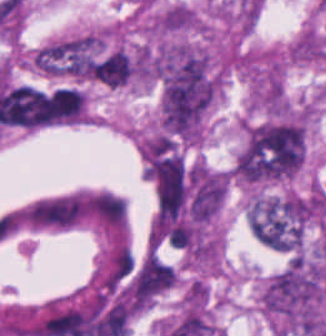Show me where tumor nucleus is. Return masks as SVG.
<instances>
[{"label": "tumor nucleus", "instance_id": "tumor-nucleus-1", "mask_svg": "<svg viewBox=\"0 0 326 336\" xmlns=\"http://www.w3.org/2000/svg\"><path fill=\"white\" fill-rule=\"evenodd\" d=\"M31 65L46 75L99 79L100 36L89 31L48 43L34 52Z\"/></svg>", "mask_w": 326, "mask_h": 336}]
</instances>
